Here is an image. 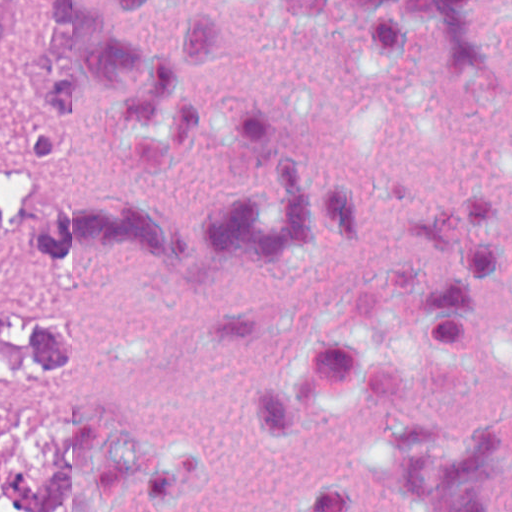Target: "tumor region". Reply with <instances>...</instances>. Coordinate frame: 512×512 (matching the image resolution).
<instances>
[{
    "mask_svg": "<svg viewBox=\"0 0 512 512\" xmlns=\"http://www.w3.org/2000/svg\"><path fill=\"white\" fill-rule=\"evenodd\" d=\"M25 55L13 0H0V136L16 133L10 100ZM30 100L48 126L45 0L27 77ZM0 248H53L122 259L235 262L220 232L184 225L112 196L0 181ZM52 313L0 293V512H60L49 462Z\"/></svg>",
    "mask_w": 512,
    "mask_h": 512,
    "instance_id": "obj_1",
    "label": "tumor region"
}]
</instances>
